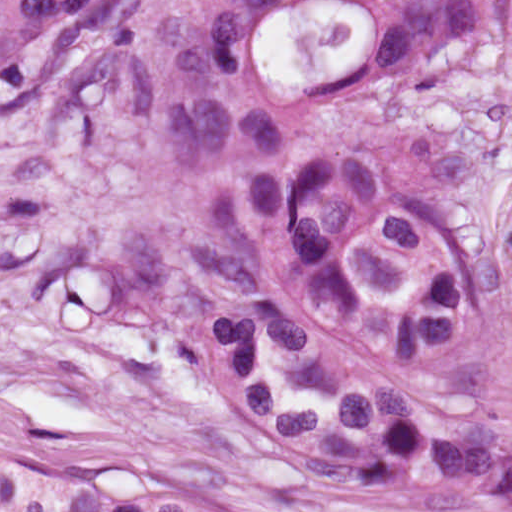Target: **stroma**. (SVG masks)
<instances>
[{
    "instance_id": "obj_1",
    "label": "stroma",
    "mask_w": 512,
    "mask_h": 512,
    "mask_svg": "<svg viewBox=\"0 0 512 512\" xmlns=\"http://www.w3.org/2000/svg\"><path fill=\"white\" fill-rule=\"evenodd\" d=\"M181 127L220 215L341 153L404 150L445 162L496 291L512 292V0L357 104ZM329 460L352 512H471Z\"/></svg>"
}]
</instances>
